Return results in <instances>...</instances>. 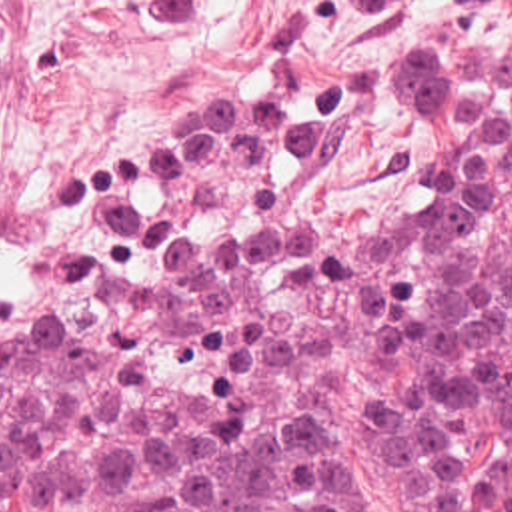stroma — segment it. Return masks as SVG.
I'll list each match as a JSON object with an SVG mask.
<instances>
[{
	"mask_svg": "<svg viewBox=\"0 0 512 512\" xmlns=\"http://www.w3.org/2000/svg\"><path fill=\"white\" fill-rule=\"evenodd\" d=\"M477 50H512V0H0V304L45 284L69 208L125 142L221 94L275 98L305 130L299 222L409 192L369 76ZM333 446L351 512H473L451 490L387 500L337 404Z\"/></svg>",
	"mask_w": 512,
	"mask_h": 512,
	"instance_id": "1",
	"label": "stroma"
}]
</instances>
